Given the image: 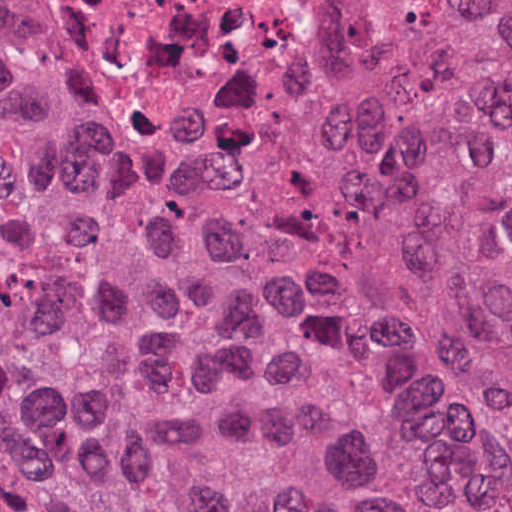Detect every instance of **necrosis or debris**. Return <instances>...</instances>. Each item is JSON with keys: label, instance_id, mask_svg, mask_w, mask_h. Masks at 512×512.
Segmentation results:
<instances>
[{"label": "necrosis or debris", "instance_id": "necrosis-or-debris-1", "mask_svg": "<svg viewBox=\"0 0 512 512\" xmlns=\"http://www.w3.org/2000/svg\"><path fill=\"white\" fill-rule=\"evenodd\" d=\"M335 29L336 0H0V50L136 162L219 160L280 128Z\"/></svg>", "mask_w": 512, "mask_h": 512}]
</instances>
